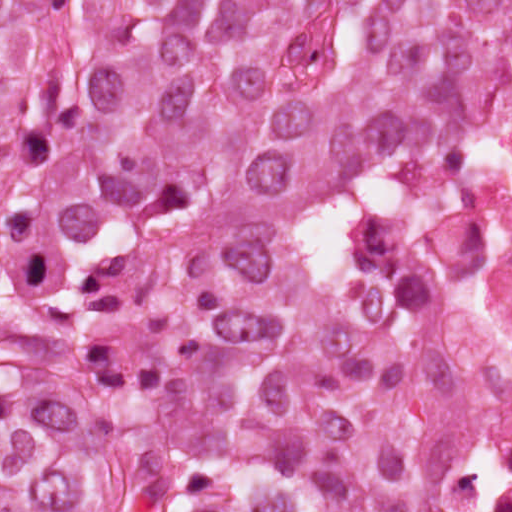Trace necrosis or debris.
Instances as JSON below:
<instances>
[{
  "label": "necrosis or debris",
  "mask_w": 512,
  "mask_h": 512,
  "mask_svg": "<svg viewBox=\"0 0 512 512\" xmlns=\"http://www.w3.org/2000/svg\"><path fill=\"white\" fill-rule=\"evenodd\" d=\"M348 276L485 367V406L437 445L421 512H512V25L477 56L420 188L356 216Z\"/></svg>",
  "instance_id": "necrosis-or-debris-1"
}]
</instances>
